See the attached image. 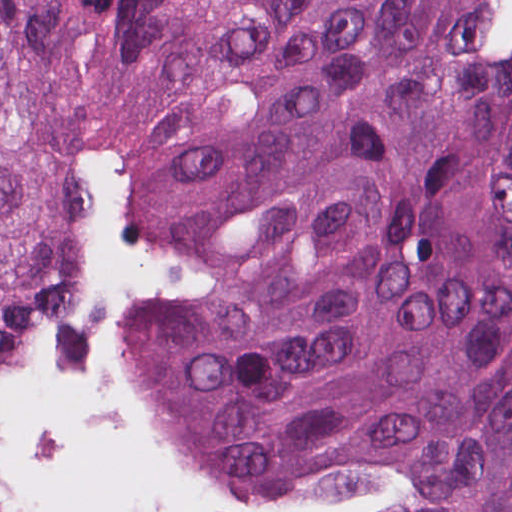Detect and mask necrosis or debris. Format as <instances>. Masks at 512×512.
I'll return each mask as SVG.
<instances>
[{
  "label": "necrosis or debris",
  "mask_w": 512,
  "mask_h": 512,
  "mask_svg": "<svg viewBox=\"0 0 512 512\" xmlns=\"http://www.w3.org/2000/svg\"><path fill=\"white\" fill-rule=\"evenodd\" d=\"M469 22L474 37L512 54V0H474Z\"/></svg>",
  "instance_id": "4bbe7bcc"
}]
</instances>
